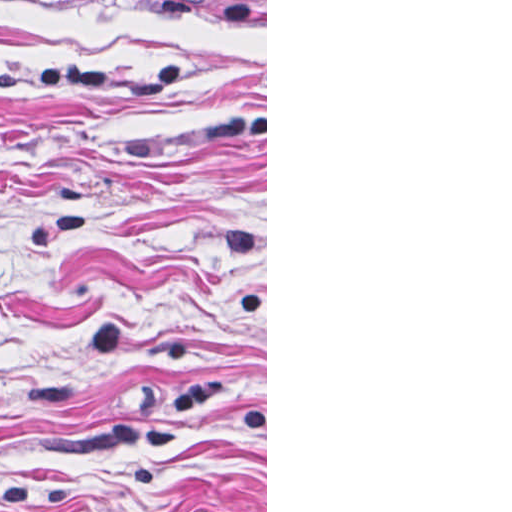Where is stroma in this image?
<instances>
[{
  "label": "stroma",
  "instance_id": "35a3bbf8",
  "mask_svg": "<svg viewBox=\"0 0 512 512\" xmlns=\"http://www.w3.org/2000/svg\"><path fill=\"white\" fill-rule=\"evenodd\" d=\"M0 512H267V0L0 1Z\"/></svg>",
  "mask_w": 512,
  "mask_h": 512
}]
</instances>
